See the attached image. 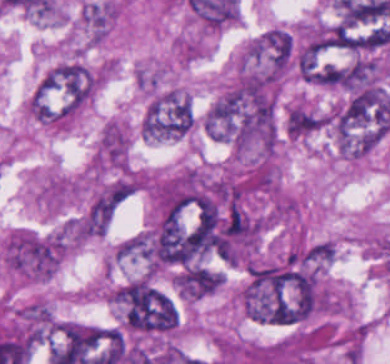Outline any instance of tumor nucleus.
Wrapping results in <instances>:
<instances>
[{
  "label": "tumor nucleus",
  "instance_id": "2f306a5c",
  "mask_svg": "<svg viewBox=\"0 0 390 364\" xmlns=\"http://www.w3.org/2000/svg\"><path fill=\"white\" fill-rule=\"evenodd\" d=\"M101 80V66L70 58L50 69L38 87L50 122L75 116L95 96Z\"/></svg>",
  "mask_w": 390,
  "mask_h": 364
},
{
  "label": "tumor nucleus",
  "instance_id": "8643909e",
  "mask_svg": "<svg viewBox=\"0 0 390 364\" xmlns=\"http://www.w3.org/2000/svg\"><path fill=\"white\" fill-rule=\"evenodd\" d=\"M195 114L187 91L174 86L156 89L143 112L140 134L152 141L178 139L194 129Z\"/></svg>",
  "mask_w": 390,
  "mask_h": 364
},
{
  "label": "tumor nucleus",
  "instance_id": "5ab6c2c4",
  "mask_svg": "<svg viewBox=\"0 0 390 364\" xmlns=\"http://www.w3.org/2000/svg\"><path fill=\"white\" fill-rule=\"evenodd\" d=\"M293 63V35L273 25L245 44L234 67L284 78Z\"/></svg>",
  "mask_w": 390,
  "mask_h": 364
},
{
  "label": "tumor nucleus",
  "instance_id": "2cbd58db",
  "mask_svg": "<svg viewBox=\"0 0 390 364\" xmlns=\"http://www.w3.org/2000/svg\"><path fill=\"white\" fill-rule=\"evenodd\" d=\"M130 139L126 125L115 119L105 121L93 153V168L124 172L129 166Z\"/></svg>",
  "mask_w": 390,
  "mask_h": 364
},
{
  "label": "tumor nucleus",
  "instance_id": "3d1891a8",
  "mask_svg": "<svg viewBox=\"0 0 390 364\" xmlns=\"http://www.w3.org/2000/svg\"><path fill=\"white\" fill-rule=\"evenodd\" d=\"M134 183L129 179H115L101 186L94 194L86 212L88 225L106 226L131 198Z\"/></svg>",
  "mask_w": 390,
  "mask_h": 364
},
{
  "label": "tumor nucleus",
  "instance_id": "2083b535",
  "mask_svg": "<svg viewBox=\"0 0 390 364\" xmlns=\"http://www.w3.org/2000/svg\"><path fill=\"white\" fill-rule=\"evenodd\" d=\"M119 12L116 1H90L80 9L79 24L89 40L101 41L112 28Z\"/></svg>",
  "mask_w": 390,
  "mask_h": 364
},
{
  "label": "tumor nucleus",
  "instance_id": "8087334f",
  "mask_svg": "<svg viewBox=\"0 0 390 364\" xmlns=\"http://www.w3.org/2000/svg\"><path fill=\"white\" fill-rule=\"evenodd\" d=\"M326 115L302 101H295L286 110V134L302 138L324 125Z\"/></svg>",
  "mask_w": 390,
  "mask_h": 364
}]
</instances>
